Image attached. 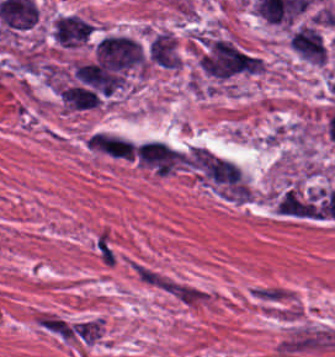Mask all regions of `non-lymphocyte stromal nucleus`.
Returning a JSON list of instances; mask_svg holds the SVG:
<instances>
[{
    "label": "non-lymphocyte stromal nucleus",
    "mask_w": 335,
    "mask_h": 357,
    "mask_svg": "<svg viewBox=\"0 0 335 357\" xmlns=\"http://www.w3.org/2000/svg\"><path fill=\"white\" fill-rule=\"evenodd\" d=\"M59 96L66 108L74 110L92 108L100 102L99 96L94 90L78 85L62 88Z\"/></svg>",
    "instance_id": "fc2b8d12"
},
{
    "label": "non-lymphocyte stromal nucleus",
    "mask_w": 335,
    "mask_h": 357,
    "mask_svg": "<svg viewBox=\"0 0 335 357\" xmlns=\"http://www.w3.org/2000/svg\"><path fill=\"white\" fill-rule=\"evenodd\" d=\"M171 296L185 307H200L207 305L209 301V291L207 289L181 280H173Z\"/></svg>",
    "instance_id": "a72fc3eb"
},
{
    "label": "non-lymphocyte stromal nucleus",
    "mask_w": 335,
    "mask_h": 357,
    "mask_svg": "<svg viewBox=\"0 0 335 357\" xmlns=\"http://www.w3.org/2000/svg\"><path fill=\"white\" fill-rule=\"evenodd\" d=\"M129 267L132 273L144 284L161 290L170 285L173 280L170 275L139 259L130 258Z\"/></svg>",
    "instance_id": "81446118"
},
{
    "label": "non-lymphocyte stromal nucleus",
    "mask_w": 335,
    "mask_h": 357,
    "mask_svg": "<svg viewBox=\"0 0 335 357\" xmlns=\"http://www.w3.org/2000/svg\"><path fill=\"white\" fill-rule=\"evenodd\" d=\"M92 249L103 268H113L116 260V250L107 228L101 227L93 234Z\"/></svg>",
    "instance_id": "7c5642bf"
},
{
    "label": "non-lymphocyte stromal nucleus",
    "mask_w": 335,
    "mask_h": 357,
    "mask_svg": "<svg viewBox=\"0 0 335 357\" xmlns=\"http://www.w3.org/2000/svg\"><path fill=\"white\" fill-rule=\"evenodd\" d=\"M134 158L138 164L157 173H171L177 165L173 146L157 138L136 144Z\"/></svg>",
    "instance_id": "dd21d789"
},
{
    "label": "non-lymphocyte stromal nucleus",
    "mask_w": 335,
    "mask_h": 357,
    "mask_svg": "<svg viewBox=\"0 0 335 357\" xmlns=\"http://www.w3.org/2000/svg\"><path fill=\"white\" fill-rule=\"evenodd\" d=\"M94 148L119 158H133V142L115 133H96Z\"/></svg>",
    "instance_id": "3746e769"
},
{
    "label": "non-lymphocyte stromal nucleus",
    "mask_w": 335,
    "mask_h": 357,
    "mask_svg": "<svg viewBox=\"0 0 335 357\" xmlns=\"http://www.w3.org/2000/svg\"><path fill=\"white\" fill-rule=\"evenodd\" d=\"M252 290L256 300L273 307L287 297L286 289L277 285H257Z\"/></svg>",
    "instance_id": "9d01c50a"
}]
</instances>
